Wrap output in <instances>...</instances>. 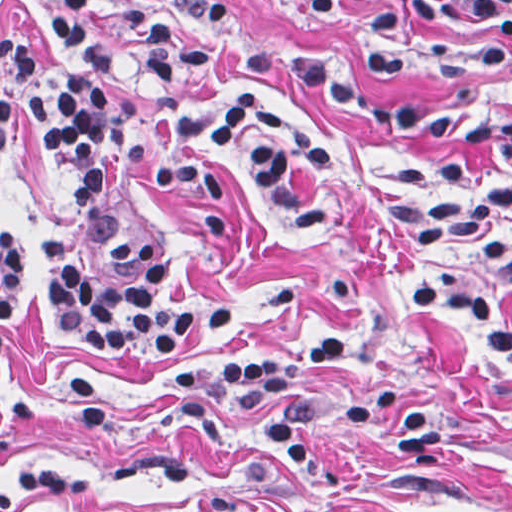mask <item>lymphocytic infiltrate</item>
Listing matches in <instances>:
<instances>
[{
  "instance_id": "f902f5d3",
  "label": "lymphocytic infiltrate",
  "mask_w": 512,
  "mask_h": 512,
  "mask_svg": "<svg viewBox=\"0 0 512 512\" xmlns=\"http://www.w3.org/2000/svg\"><path fill=\"white\" fill-rule=\"evenodd\" d=\"M103 2L49 0L45 24L62 63L51 93L34 90L44 48L0 30V144L20 111L65 191L66 203L39 244V262L68 344L95 353H174L200 330H228L231 310L213 305L174 313L157 306L168 266L145 235L105 239L112 277L100 289L86 285L66 243L99 203L111 165L141 170L154 156L121 114L110 85L120 64L89 25ZM242 8L238 0H123L116 9V21L140 46L142 87L160 106L161 130L174 144L149 172L150 186L181 209L197 238L214 245L229 233L228 169L258 188L279 225L320 219L329 206L342 156L332 137L261 88L212 95L200 83L212 70H272L344 114L452 155L463 167L401 154L379 183L382 201L408 243L460 258L512 294V122L369 103L355 85L387 77L416 51L445 74L485 75L512 50V0H375L360 21L368 39L310 55L242 31L236 24ZM20 293L17 240L0 223V372L3 326ZM405 298L411 313L443 336L512 366L511 303L450 274L408 280ZM347 358L342 334L329 333L245 361L185 363L162 387L169 394L205 390L181 409L179 421L206 442H230L221 403L267 412L261 439L283 471L304 484L306 512H342L350 459L345 452L326 457L316 442L318 395L299 389L297 379L308 367ZM346 412L356 422L394 412L390 433L401 460L433 465L441 423L416 388L366 387L347 400ZM77 492L78 479L65 466L15 472L0 481V512Z\"/></svg>"
}]
</instances>
